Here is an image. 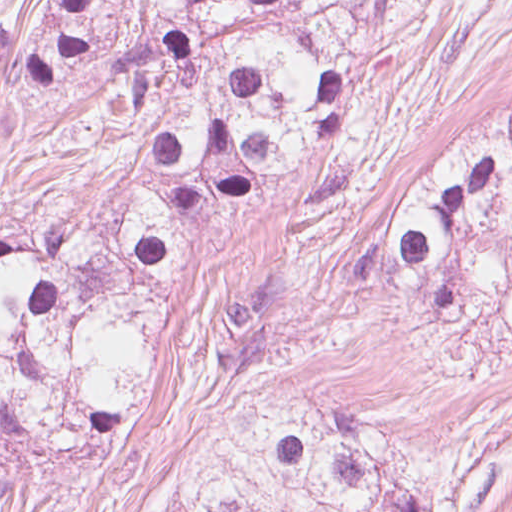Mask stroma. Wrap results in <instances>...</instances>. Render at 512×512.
<instances>
[{"instance_id":"obj_1","label":"stroma","mask_w":512,"mask_h":512,"mask_svg":"<svg viewBox=\"0 0 512 512\" xmlns=\"http://www.w3.org/2000/svg\"><path fill=\"white\" fill-rule=\"evenodd\" d=\"M249 368L174 343L154 397L122 438L93 456H35L0 512H159L174 476L199 452L227 375ZM412 433L444 430L322 392ZM490 512H512V502Z\"/></svg>"}]
</instances>
